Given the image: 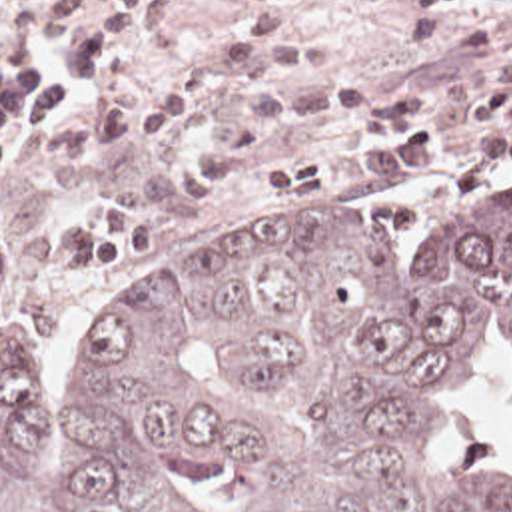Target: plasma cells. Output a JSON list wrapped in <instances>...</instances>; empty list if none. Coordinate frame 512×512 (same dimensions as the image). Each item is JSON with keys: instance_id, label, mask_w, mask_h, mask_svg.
Returning a JSON list of instances; mask_svg holds the SVG:
<instances>
[{"instance_id": "9512152a", "label": "plasma cells", "mask_w": 512, "mask_h": 512, "mask_svg": "<svg viewBox=\"0 0 512 512\" xmlns=\"http://www.w3.org/2000/svg\"><path fill=\"white\" fill-rule=\"evenodd\" d=\"M234 41L138 97L118 95L144 55L174 27L176 0H16L0 25V170L28 146L36 164H70L168 141L184 115L228 89L236 105L218 141L176 170L18 232L14 268L26 276H88L130 266L188 214L222 192L254 154L299 129L349 123L351 141L279 158L265 198L289 200L333 182L433 160L429 113L477 89L512 83V47L451 75L381 95L367 83H321L333 55L285 27L299 0H248Z\"/></svg>"}]
</instances>
